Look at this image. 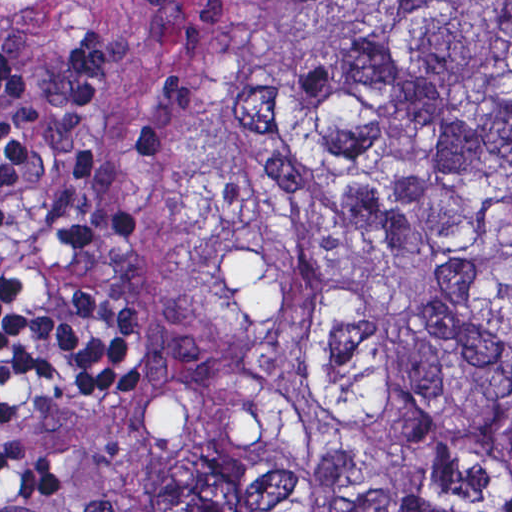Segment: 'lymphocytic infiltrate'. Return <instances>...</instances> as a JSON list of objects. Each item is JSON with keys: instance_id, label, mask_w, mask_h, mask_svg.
I'll return each mask as SVG.
<instances>
[{"instance_id": "f902f5d3", "label": "lymphocytic infiltrate", "mask_w": 512, "mask_h": 512, "mask_svg": "<svg viewBox=\"0 0 512 512\" xmlns=\"http://www.w3.org/2000/svg\"><path fill=\"white\" fill-rule=\"evenodd\" d=\"M150 346L129 230L73 149L22 119L0 67V512L60 508V472L2 425L10 402L113 400Z\"/></svg>"}]
</instances>
